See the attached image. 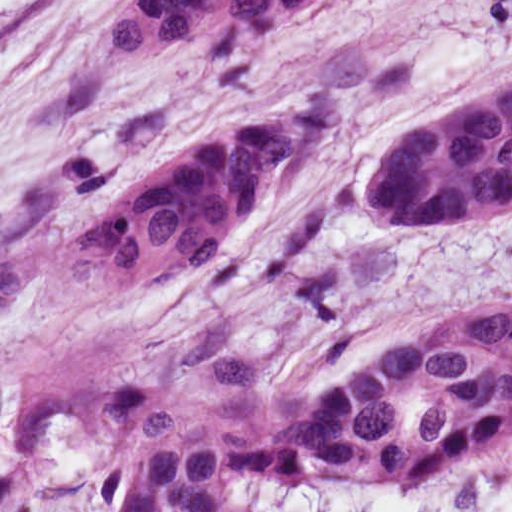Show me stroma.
<instances>
[{"mask_svg":"<svg viewBox=\"0 0 512 512\" xmlns=\"http://www.w3.org/2000/svg\"><path fill=\"white\" fill-rule=\"evenodd\" d=\"M124 0H0V196L441 0H344L309 32L214 62H133Z\"/></svg>","mask_w":512,"mask_h":512,"instance_id":"1","label":"stroma"}]
</instances>
